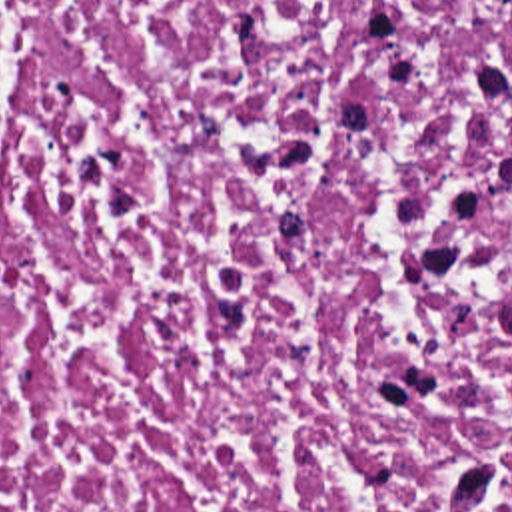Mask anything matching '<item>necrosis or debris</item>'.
I'll list each match as a JSON object with an SVG mask.
<instances>
[{
    "label": "necrosis or debris",
    "mask_w": 512,
    "mask_h": 512,
    "mask_svg": "<svg viewBox=\"0 0 512 512\" xmlns=\"http://www.w3.org/2000/svg\"><path fill=\"white\" fill-rule=\"evenodd\" d=\"M0 512H512V0H0Z\"/></svg>",
    "instance_id": "4bbe7bcc"
}]
</instances>
